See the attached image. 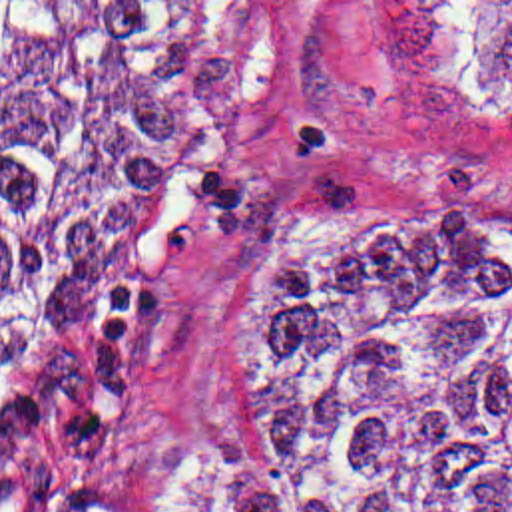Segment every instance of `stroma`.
<instances>
[{
  "mask_svg": "<svg viewBox=\"0 0 512 512\" xmlns=\"http://www.w3.org/2000/svg\"><path fill=\"white\" fill-rule=\"evenodd\" d=\"M197 2L209 125L169 167L135 253V339L112 388L42 430L28 490L0 512H110L130 466H255L237 436L259 265L297 211L382 163L460 169L512 197V92L490 90L450 2Z\"/></svg>",
  "mask_w": 512,
  "mask_h": 512,
  "instance_id": "stroma-1",
  "label": "stroma"
}]
</instances>
